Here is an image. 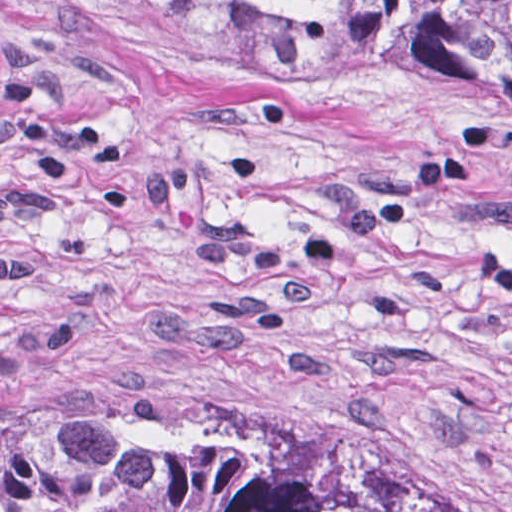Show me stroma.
Segmentation results:
<instances>
[{
	"label": "stroma",
	"instance_id": "35a3bbf8",
	"mask_svg": "<svg viewBox=\"0 0 512 512\" xmlns=\"http://www.w3.org/2000/svg\"><path fill=\"white\" fill-rule=\"evenodd\" d=\"M491 249L510 109L197 77L0 8V384L141 372L512 512Z\"/></svg>",
	"mask_w": 512,
	"mask_h": 512
}]
</instances>
